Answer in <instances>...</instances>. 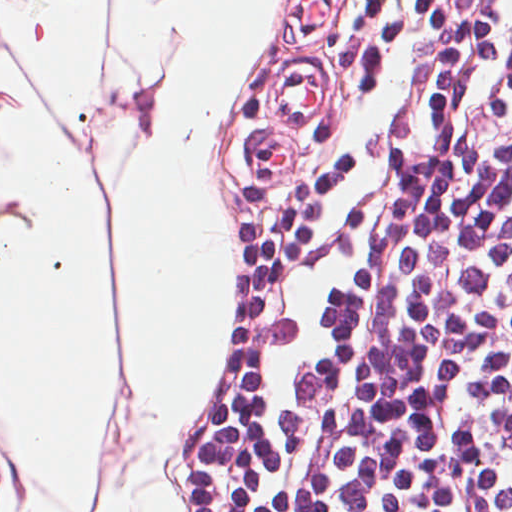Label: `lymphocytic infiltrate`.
<instances>
[{"instance_id":"lymphocytic-infiltrate-1","label":"lymphocytic infiltrate","mask_w":512,"mask_h":512,"mask_svg":"<svg viewBox=\"0 0 512 512\" xmlns=\"http://www.w3.org/2000/svg\"><path fill=\"white\" fill-rule=\"evenodd\" d=\"M463 512H512V284Z\"/></svg>"}]
</instances>
